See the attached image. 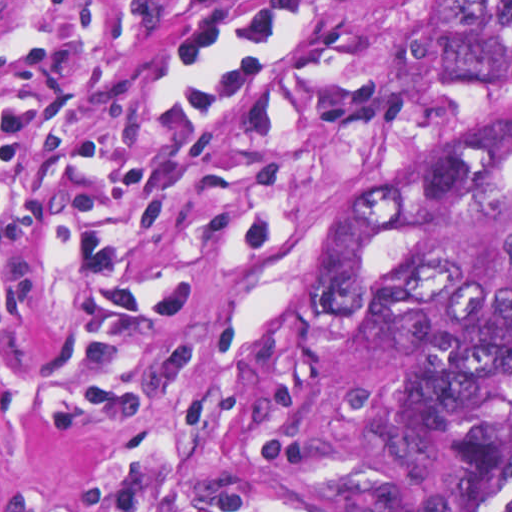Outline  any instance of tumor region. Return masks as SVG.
I'll list each match as a JSON object with an SVG mask.
<instances>
[{
	"label": "tumor region",
	"instance_id": "tumor-region-1",
	"mask_svg": "<svg viewBox=\"0 0 512 512\" xmlns=\"http://www.w3.org/2000/svg\"><path fill=\"white\" fill-rule=\"evenodd\" d=\"M397 177L341 187L243 382L197 512H512V1H442L394 55Z\"/></svg>",
	"mask_w": 512,
	"mask_h": 512
}]
</instances>
